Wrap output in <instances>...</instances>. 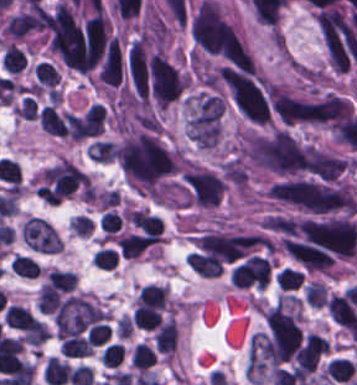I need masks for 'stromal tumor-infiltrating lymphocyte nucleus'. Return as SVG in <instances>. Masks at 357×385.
Wrapping results in <instances>:
<instances>
[{"instance_id":"obj_1","label":"stromal tumor-infiltrating lymphocyte nucleus","mask_w":357,"mask_h":385,"mask_svg":"<svg viewBox=\"0 0 357 385\" xmlns=\"http://www.w3.org/2000/svg\"><path fill=\"white\" fill-rule=\"evenodd\" d=\"M105 111L98 103H90L79 120V140L103 132Z\"/></svg>"},{"instance_id":"obj_2","label":"stromal tumor-infiltrating lymphocyte nucleus","mask_w":357,"mask_h":385,"mask_svg":"<svg viewBox=\"0 0 357 385\" xmlns=\"http://www.w3.org/2000/svg\"><path fill=\"white\" fill-rule=\"evenodd\" d=\"M76 278L73 271L48 268L41 285L52 292L70 293Z\"/></svg>"},{"instance_id":"obj_3","label":"stromal tumor-infiltrating lymphocyte nucleus","mask_w":357,"mask_h":385,"mask_svg":"<svg viewBox=\"0 0 357 385\" xmlns=\"http://www.w3.org/2000/svg\"><path fill=\"white\" fill-rule=\"evenodd\" d=\"M0 64L9 75H17L25 67L26 61L21 49L10 41L2 51Z\"/></svg>"},{"instance_id":"obj_4","label":"stromal tumor-infiltrating lymphocyte nucleus","mask_w":357,"mask_h":385,"mask_svg":"<svg viewBox=\"0 0 357 385\" xmlns=\"http://www.w3.org/2000/svg\"><path fill=\"white\" fill-rule=\"evenodd\" d=\"M10 272L17 277L26 279H36L39 270L38 265L32 257L28 255L15 254L9 262Z\"/></svg>"},{"instance_id":"obj_5","label":"stromal tumor-infiltrating lymphocyte nucleus","mask_w":357,"mask_h":385,"mask_svg":"<svg viewBox=\"0 0 357 385\" xmlns=\"http://www.w3.org/2000/svg\"><path fill=\"white\" fill-rule=\"evenodd\" d=\"M37 86L54 87L60 78L58 70L51 62L38 61L32 69Z\"/></svg>"},{"instance_id":"obj_6","label":"stromal tumor-infiltrating lymphocyte nucleus","mask_w":357,"mask_h":385,"mask_svg":"<svg viewBox=\"0 0 357 385\" xmlns=\"http://www.w3.org/2000/svg\"><path fill=\"white\" fill-rule=\"evenodd\" d=\"M90 259L95 267L104 271H113L118 262V253L111 248L99 247Z\"/></svg>"},{"instance_id":"obj_7","label":"stromal tumor-infiltrating lymphocyte nucleus","mask_w":357,"mask_h":385,"mask_svg":"<svg viewBox=\"0 0 357 385\" xmlns=\"http://www.w3.org/2000/svg\"><path fill=\"white\" fill-rule=\"evenodd\" d=\"M110 332L109 324L93 323L86 332L87 341L92 345L99 346L105 344Z\"/></svg>"},{"instance_id":"obj_8","label":"stromal tumor-infiltrating lymphocyte nucleus","mask_w":357,"mask_h":385,"mask_svg":"<svg viewBox=\"0 0 357 385\" xmlns=\"http://www.w3.org/2000/svg\"><path fill=\"white\" fill-rule=\"evenodd\" d=\"M36 115L37 105L31 96H24L14 108V116L22 119L34 121L36 119Z\"/></svg>"}]
</instances>
